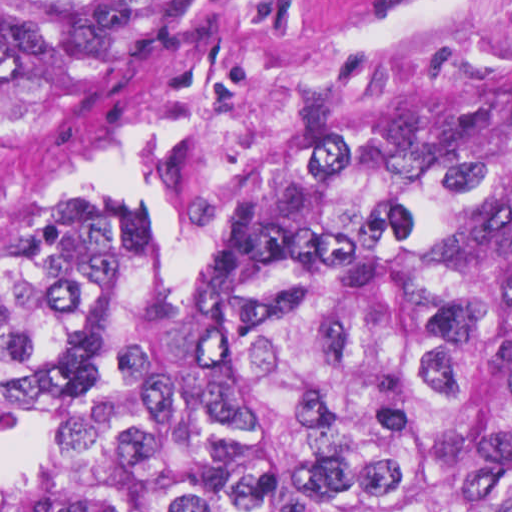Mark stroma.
Returning a JSON list of instances; mask_svg holds the SVG:
<instances>
[{
  "mask_svg": "<svg viewBox=\"0 0 512 512\" xmlns=\"http://www.w3.org/2000/svg\"><path fill=\"white\" fill-rule=\"evenodd\" d=\"M344 77L497 83L512 91V0H239L57 131L0 157V238L25 191L80 183L152 213L161 278L230 262L271 128ZM0 432V512L40 498Z\"/></svg>",
  "mask_w": 512,
  "mask_h": 512,
  "instance_id": "35a3bbf8",
  "label": "stroma"
}]
</instances>
